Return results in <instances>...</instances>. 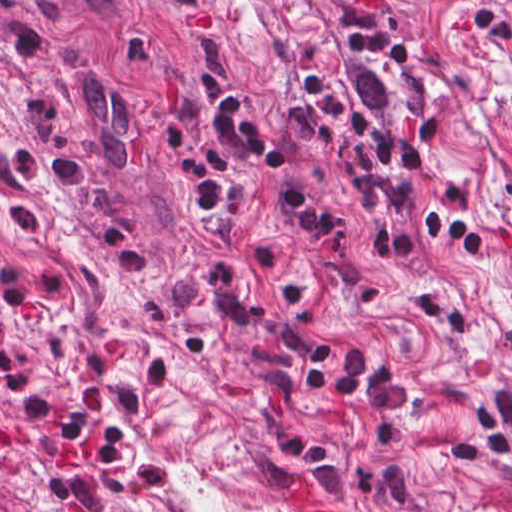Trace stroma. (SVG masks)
Returning <instances> with one entry per match:
<instances>
[{"instance_id":"1","label":"stroma","mask_w":512,"mask_h":512,"mask_svg":"<svg viewBox=\"0 0 512 512\" xmlns=\"http://www.w3.org/2000/svg\"><path fill=\"white\" fill-rule=\"evenodd\" d=\"M512 504L0 44V481L35 512Z\"/></svg>"}]
</instances>
